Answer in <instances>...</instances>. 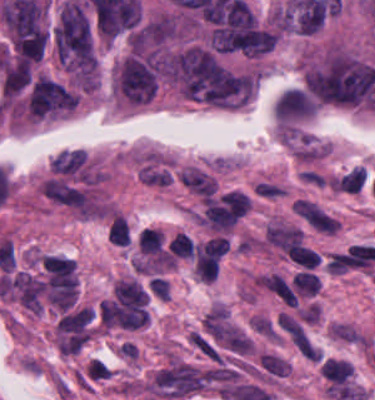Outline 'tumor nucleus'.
I'll return each mask as SVG.
<instances>
[{
	"label": "tumor nucleus",
	"instance_id": "2cbd58db",
	"mask_svg": "<svg viewBox=\"0 0 375 400\" xmlns=\"http://www.w3.org/2000/svg\"><path fill=\"white\" fill-rule=\"evenodd\" d=\"M116 85L134 102H146L157 88V72L153 63L146 58L129 55L120 63Z\"/></svg>",
	"mask_w": 375,
	"mask_h": 400
},
{
	"label": "tumor nucleus",
	"instance_id": "5ab6c2c4",
	"mask_svg": "<svg viewBox=\"0 0 375 400\" xmlns=\"http://www.w3.org/2000/svg\"><path fill=\"white\" fill-rule=\"evenodd\" d=\"M94 34L69 0L53 26V41L75 74Z\"/></svg>",
	"mask_w": 375,
	"mask_h": 400
},
{
	"label": "tumor nucleus",
	"instance_id": "2f306a5c",
	"mask_svg": "<svg viewBox=\"0 0 375 400\" xmlns=\"http://www.w3.org/2000/svg\"><path fill=\"white\" fill-rule=\"evenodd\" d=\"M168 74L193 99L229 106L246 101L247 74L206 48L168 54Z\"/></svg>",
	"mask_w": 375,
	"mask_h": 400
},
{
	"label": "tumor nucleus",
	"instance_id": "8643909e",
	"mask_svg": "<svg viewBox=\"0 0 375 400\" xmlns=\"http://www.w3.org/2000/svg\"><path fill=\"white\" fill-rule=\"evenodd\" d=\"M310 94L322 101L357 104L375 83L370 64L334 52L305 71Z\"/></svg>",
	"mask_w": 375,
	"mask_h": 400
},
{
	"label": "tumor nucleus",
	"instance_id": "2083b535",
	"mask_svg": "<svg viewBox=\"0 0 375 400\" xmlns=\"http://www.w3.org/2000/svg\"><path fill=\"white\" fill-rule=\"evenodd\" d=\"M31 77L32 73L28 59L19 56L4 64L0 89L5 95H13L29 83Z\"/></svg>",
	"mask_w": 375,
	"mask_h": 400
},
{
	"label": "tumor nucleus",
	"instance_id": "3d1891a8",
	"mask_svg": "<svg viewBox=\"0 0 375 400\" xmlns=\"http://www.w3.org/2000/svg\"><path fill=\"white\" fill-rule=\"evenodd\" d=\"M76 100V94L66 86L41 76L33 83L28 109L43 117L73 109Z\"/></svg>",
	"mask_w": 375,
	"mask_h": 400
}]
</instances>
